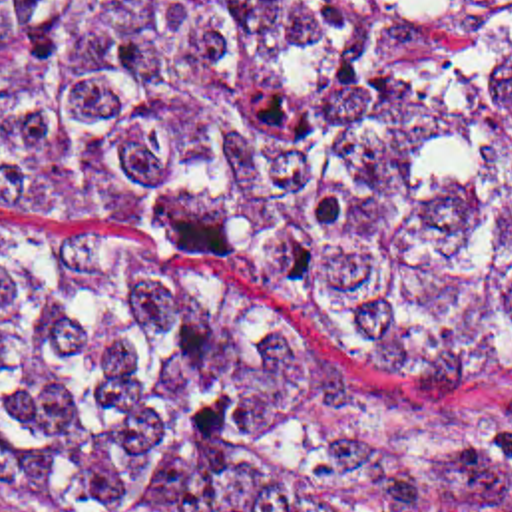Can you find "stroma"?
<instances>
[{"mask_svg": "<svg viewBox=\"0 0 512 512\" xmlns=\"http://www.w3.org/2000/svg\"><path fill=\"white\" fill-rule=\"evenodd\" d=\"M0 242L62 252L83 264L125 268L225 306L293 353L382 397H420L440 407H478L512 419V373L386 346L287 308L251 288L133 238H72L0 196ZM0 512H38L0 505Z\"/></svg>", "mask_w": 512, "mask_h": 512, "instance_id": "35a3bbf8", "label": "stroma"}]
</instances>
